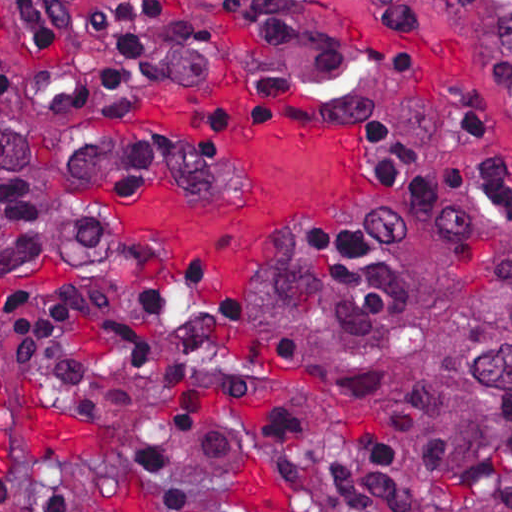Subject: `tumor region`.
<instances>
[{"label":"tumor region","mask_w":512,"mask_h":512,"mask_svg":"<svg viewBox=\"0 0 512 512\" xmlns=\"http://www.w3.org/2000/svg\"><path fill=\"white\" fill-rule=\"evenodd\" d=\"M95 172L0 46V291L93 252ZM370 195V214L266 295L281 365L366 441L359 512H512V216Z\"/></svg>","instance_id":"1"}]
</instances>
